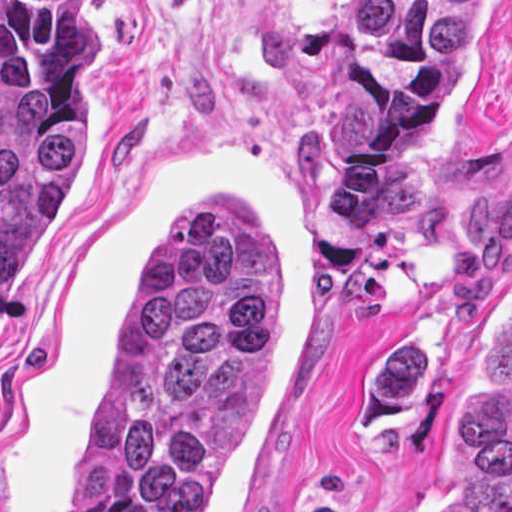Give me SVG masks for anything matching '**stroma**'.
<instances>
[{
  "label": "stroma",
  "instance_id": "1",
  "mask_svg": "<svg viewBox=\"0 0 512 512\" xmlns=\"http://www.w3.org/2000/svg\"><path fill=\"white\" fill-rule=\"evenodd\" d=\"M334 0H94L84 160L0 314V512H76V444L148 267L250 204L278 400L207 512H432L445 388L512 283V0L381 252L331 226Z\"/></svg>",
  "mask_w": 512,
  "mask_h": 512
}]
</instances>
